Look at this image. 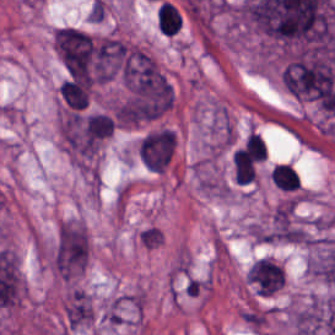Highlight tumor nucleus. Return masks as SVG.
<instances>
[{"label":"tumor nucleus","instance_id":"2f306a5c","mask_svg":"<svg viewBox=\"0 0 335 335\" xmlns=\"http://www.w3.org/2000/svg\"><path fill=\"white\" fill-rule=\"evenodd\" d=\"M108 129V119L98 112H61L58 118L61 144L74 161L93 158Z\"/></svg>","mask_w":335,"mask_h":335},{"label":"tumor nucleus","instance_id":"8643909e","mask_svg":"<svg viewBox=\"0 0 335 335\" xmlns=\"http://www.w3.org/2000/svg\"><path fill=\"white\" fill-rule=\"evenodd\" d=\"M285 278L283 267L273 258L259 256L247 267L245 282L254 295L270 296L279 290Z\"/></svg>","mask_w":335,"mask_h":335},{"label":"tumor nucleus","instance_id":"5ab6c2c4","mask_svg":"<svg viewBox=\"0 0 335 335\" xmlns=\"http://www.w3.org/2000/svg\"><path fill=\"white\" fill-rule=\"evenodd\" d=\"M269 175L273 186L280 192L298 196L299 182L296 169L285 163H277L272 166Z\"/></svg>","mask_w":335,"mask_h":335}]
</instances>
